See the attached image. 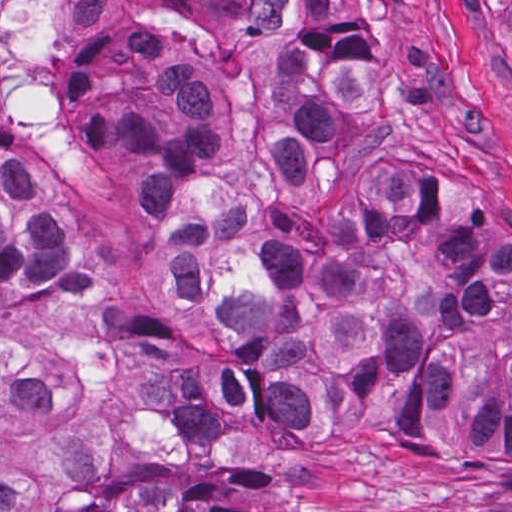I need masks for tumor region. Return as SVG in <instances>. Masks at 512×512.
<instances>
[{"instance_id":"1","label":"tumor region","mask_w":512,"mask_h":512,"mask_svg":"<svg viewBox=\"0 0 512 512\" xmlns=\"http://www.w3.org/2000/svg\"><path fill=\"white\" fill-rule=\"evenodd\" d=\"M249 112L225 120L199 59L133 48L108 109L140 182L151 264L235 357L134 329L100 299L67 193L0 168V298L15 332L126 360L158 435L247 425L313 435L395 424L433 469L512 466V252L428 194L387 141L371 37L336 0H245ZM512 55V0H473ZM0 512H252L220 479L124 476L110 429L49 394L30 349L0 350Z\"/></svg>"}]
</instances>
